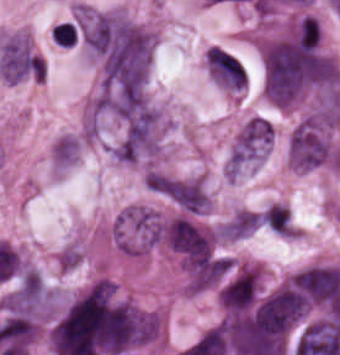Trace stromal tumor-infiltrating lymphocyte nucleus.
<instances>
[{
    "mask_svg": "<svg viewBox=\"0 0 340 355\" xmlns=\"http://www.w3.org/2000/svg\"><path fill=\"white\" fill-rule=\"evenodd\" d=\"M51 37L62 46H72L77 41V29L73 22L63 21L51 28Z\"/></svg>",
    "mask_w": 340,
    "mask_h": 355,
    "instance_id": "stromal-tumor-infiltrating-lymphocyte-nucleus-1",
    "label": "stromal tumor-infiltrating lymphocyte nucleus"
}]
</instances>
